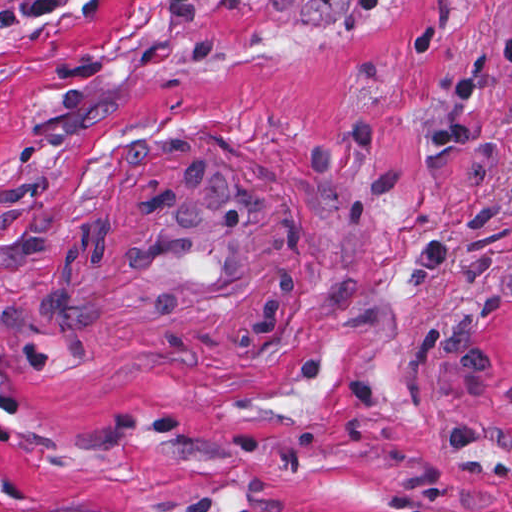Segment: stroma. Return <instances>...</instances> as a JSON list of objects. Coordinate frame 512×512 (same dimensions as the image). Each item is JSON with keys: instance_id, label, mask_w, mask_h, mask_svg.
<instances>
[{"instance_id": "35a3bbf8", "label": "stroma", "mask_w": 512, "mask_h": 512, "mask_svg": "<svg viewBox=\"0 0 512 512\" xmlns=\"http://www.w3.org/2000/svg\"><path fill=\"white\" fill-rule=\"evenodd\" d=\"M214 157L272 285L100 286ZM0 512H512V0H0Z\"/></svg>"}]
</instances>
